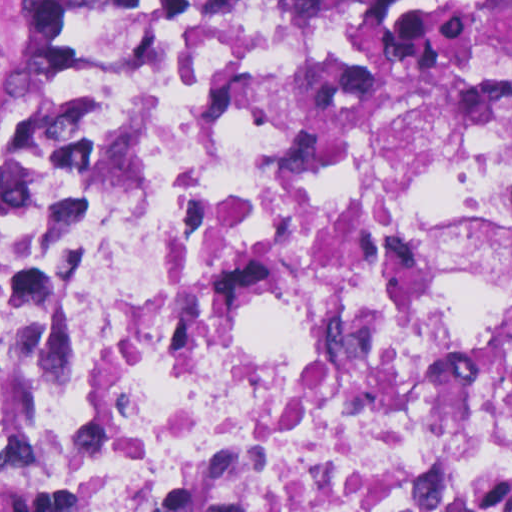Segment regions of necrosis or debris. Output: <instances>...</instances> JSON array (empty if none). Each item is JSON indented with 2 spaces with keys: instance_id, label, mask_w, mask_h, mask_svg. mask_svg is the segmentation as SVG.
Returning <instances> with one entry per match:
<instances>
[{
  "instance_id": "obj_1",
  "label": "necrosis or debris",
  "mask_w": 512,
  "mask_h": 512,
  "mask_svg": "<svg viewBox=\"0 0 512 512\" xmlns=\"http://www.w3.org/2000/svg\"><path fill=\"white\" fill-rule=\"evenodd\" d=\"M512 512V26L100 0L0 164V512Z\"/></svg>"
}]
</instances>
